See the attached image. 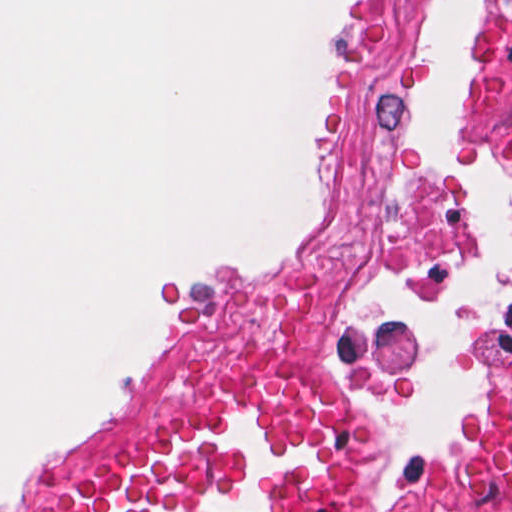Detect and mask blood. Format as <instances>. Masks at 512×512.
<instances>
[{"label":"blood","instance_id":"obj_1","mask_svg":"<svg viewBox=\"0 0 512 512\" xmlns=\"http://www.w3.org/2000/svg\"><path fill=\"white\" fill-rule=\"evenodd\" d=\"M377 472V424L359 404L288 362L243 356L21 512H359Z\"/></svg>","mask_w":512,"mask_h":512}]
</instances>
